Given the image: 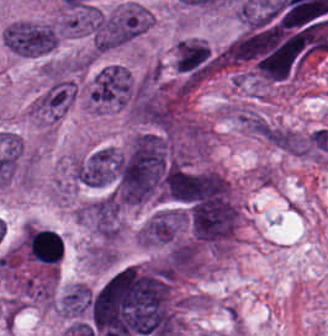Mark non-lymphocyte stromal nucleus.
<instances>
[{"instance_id":"dd21d789","label":"non-lymphocyte stromal nucleus","mask_w":328,"mask_h":336,"mask_svg":"<svg viewBox=\"0 0 328 336\" xmlns=\"http://www.w3.org/2000/svg\"><path fill=\"white\" fill-rule=\"evenodd\" d=\"M254 132L281 152L291 155H308L309 132L272 121L261 123Z\"/></svg>"}]
</instances>
